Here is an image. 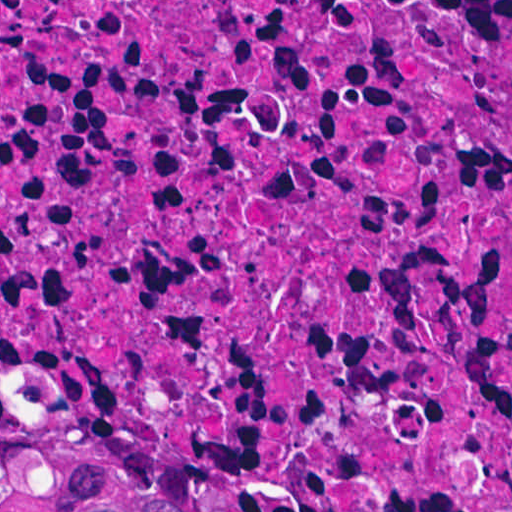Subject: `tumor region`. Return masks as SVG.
Returning a JSON list of instances; mask_svg holds the SVG:
<instances>
[{"label": "tumor region", "mask_w": 512, "mask_h": 512, "mask_svg": "<svg viewBox=\"0 0 512 512\" xmlns=\"http://www.w3.org/2000/svg\"><path fill=\"white\" fill-rule=\"evenodd\" d=\"M0 512H243L85 425L0 404Z\"/></svg>", "instance_id": "e687c5a6"}]
</instances>
